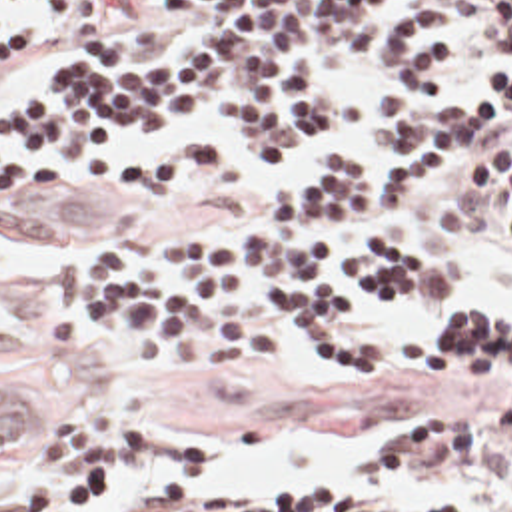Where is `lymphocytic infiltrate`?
Listing matches in <instances>:
<instances>
[{
	"mask_svg": "<svg viewBox=\"0 0 512 512\" xmlns=\"http://www.w3.org/2000/svg\"><path fill=\"white\" fill-rule=\"evenodd\" d=\"M501 51L477 103L446 95L469 49ZM376 49L406 85L356 119L364 144L320 154L284 178L246 238L192 230L118 238L58 258L38 320L62 340L84 328L126 354L178 348L202 360H258L294 338L344 368L412 382L512 386V314L483 338L408 346L356 318L378 292H436L456 268L396 228L430 166L463 174L430 198L454 230L512 244V0H0V87L58 59L0 103V133L62 164H112L132 146L108 125L166 129L204 103L226 144L270 164L350 119L354 91L314 71L318 55ZM380 158V164H378ZM56 178L0 156V208H56ZM284 314L286 320L276 314ZM302 320L300 324L294 320ZM196 422L54 416L24 448L36 468L8 512H76L142 464H192L170 442ZM457 472L473 496L416 512H512V400L428 410L394 428L378 476ZM120 512H402L316 480L268 496L156 486Z\"/></svg>",
	"mask_w": 512,
	"mask_h": 512,
	"instance_id": "1",
	"label": "lymphocytic infiltrate"
}]
</instances>
